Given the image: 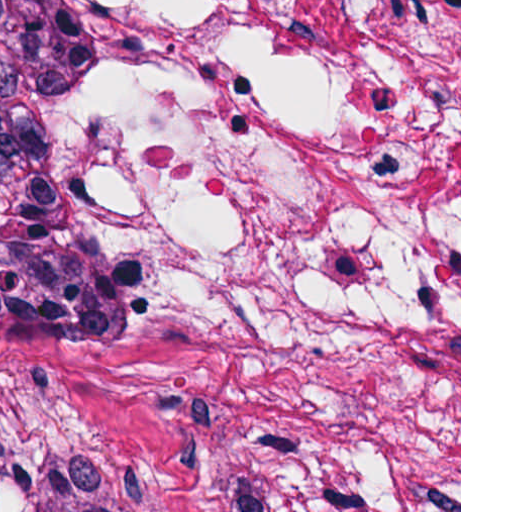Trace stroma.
<instances>
[{"label": "stroma", "instance_id": "obj_1", "mask_svg": "<svg viewBox=\"0 0 512 512\" xmlns=\"http://www.w3.org/2000/svg\"><path fill=\"white\" fill-rule=\"evenodd\" d=\"M66 2L98 372L0 373V512H461V0Z\"/></svg>", "mask_w": 512, "mask_h": 512}]
</instances>
